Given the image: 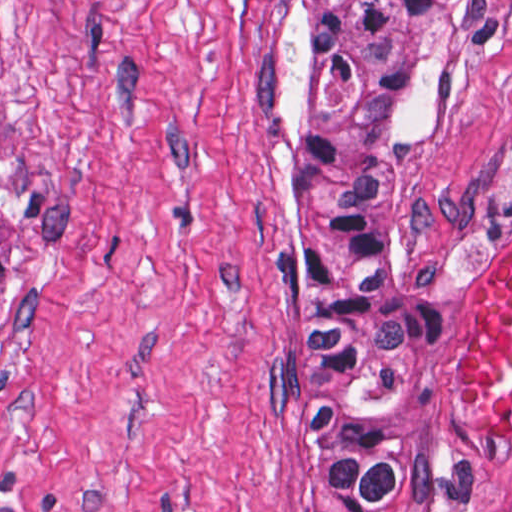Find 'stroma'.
Returning <instances> with one entry per match:
<instances>
[{"label":"stroma","mask_w":512,"mask_h":512,"mask_svg":"<svg viewBox=\"0 0 512 512\" xmlns=\"http://www.w3.org/2000/svg\"><path fill=\"white\" fill-rule=\"evenodd\" d=\"M296 0H0V512H325L288 376ZM512 237V0H478L438 123L380 179L384 264L440 325L408 497L512 462L461 399Z\"/></svg>","instance_id":"35a3bbf8"}]
</instances>
